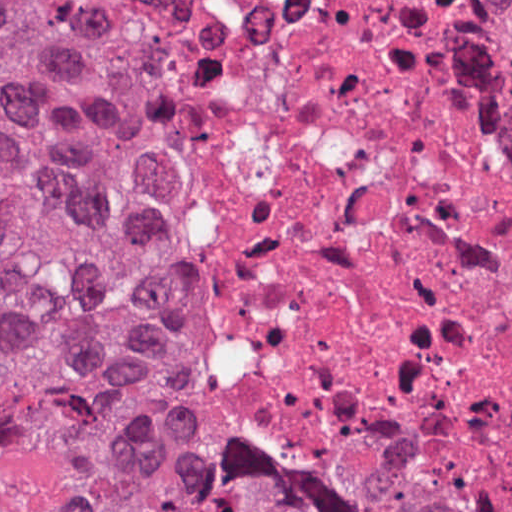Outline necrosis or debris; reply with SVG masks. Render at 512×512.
<instances>
[{
    "mask_svg": "<svg viewBox=\"0 0 512 512\" xmlns=\"http://www.w3.org/2000/svg\"><path fill=\"white\" fill-rule=\"evenodd\" d=\"M130 107L204 424L394 512L512 509V36L488 0H67Z\"/></svg>",
    "mask_w": 512,
    "mask_h": 512,
    "instance_id": "1",
    "label": "necrosis or debris"
}]
</instances>
